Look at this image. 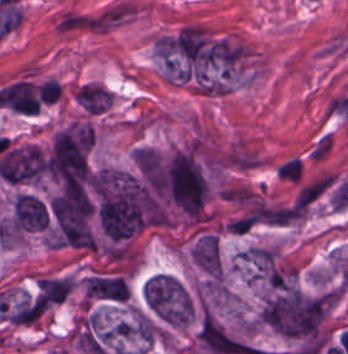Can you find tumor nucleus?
Listing matches in <instances>:
<instances>
[{
    "label": "tumor nucleus",
    "mask_w": 348,
    "mask_h": 354,
    "mask_svg": "<svg viewBox=\"0 0 348 354\" xmlns=\"http://www.w3.org/2000/svg\"><path fill=\"white\" fill-rule=\"evenodd\" d=\"M150 310L166 325L183 326L193 314V304L182 285Z\"/></svg>",
    "instance_id": "2cbd58db"
},
{
    "label": "tumor nucleus",
    "mask_w": 348,
    "mask_h": 354,
    "mask_svg": "<svg viewBox=\"0 0 348 354\" xmlns=\"http://www.w3.org/2000/svg\"><path fill=\"white\" fill-rule=\"evenodd\" d=\"M87 181L95 223L110 243L167 224V199L141 161L104 166Z\"/></svg>",
    "instance_id": "2f306a5c"
},
{
    "label": "tumor nucleus",
    "mask_w": 348,
    "mask_h": 354,
    "mask_svg": "<svg viewBox=\"0 0 348 354\" xmlns=\"http://www.w3.org/2000/svg\"><path fill=\"white\" fill-rule=\"evenodd\" d=\"M74 93L87 113L98 114L111 103L107 89L94 83H81Z\"/></svg>",
    "instance_id": "8087334f"
},
{
    "label": "tumor nucleus",
    "mask_w": 348,
    "mask_h": 354,
    "mask_svg": "<svg viewBox=\"0 0 348 354\" xmlns=\"http://www.w3.org/2000/svg\"><path fill=\"white\" fill-rule=\"evenodd\" d=\"M74 279L68 276L42 277L37 284L38 296L50 304H62L73 290Z\"/></svg>",
    "instance_id": "2083b535"
},
{
    "label": "tumor nucleus",
    "mask_w": 348,
    "mask_h": 354,
    "mask_svg": "<svg viewBox=\"0 0 348 354\" xmlns=\"http://www.w3.org/2000/svg\"><path fill=\"white\" fill-rule=\"evenodd\" d=\"M87 299L124 303L129 293V285L116 273H97L89 275L83 281Z\"/></svg>",
    "instance_id": "5ab6c2c4"
},
{
    "label": "tumor nucleus",
    "mask_w": 348,
    "mask_h": 354,
    "mask_svg": "<svg viewBox=\"0 0 348 354\" xmlns=\"http://www.w3.org/2000/svg\"><path fill=\"white\" fill-rule=\"evenodd\" d=\"M93 133L89 124L74 122L57 130L45 162L47 174L57 179L88 176Z\"/></svg>",
    "instance_id": "8643909e"
},
{
    "label": "tumor nucleus",
    "mask_w": 348,
    "mask_h": 354,
    "mask_svg": "<svg viewBox=\"0 0 348 354\" xmlns=\"http://www.w3.org/2000/svg\"><path fill=\"white\" fill-rule=\"evenodd\" d=\"M195 265L208 274H220L219 243L214 233H201L195 238L190 251Z\"/></svg>",
    "instance_id": "3d1891a8"
}]
</instances>
